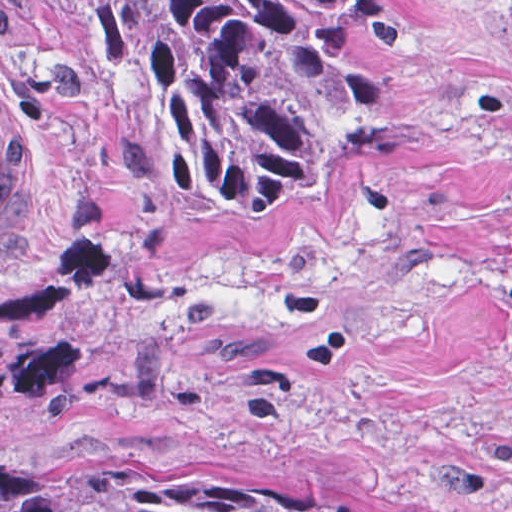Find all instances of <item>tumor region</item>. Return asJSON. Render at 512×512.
Instances as JSON below:
<instances>
[{
	"label": "tumor region",
	"mask_w": 512,
	"mask_h": 512,
	"mask_svg": "<svg viewBox=\"0 0 512 512\" xmlns=\"http://www.w3.org/2000/svg\"><path fill=\"white\" fill-rule=\"evenodd\" d=\"M25 1L218 214L258 215L337 177L394 114L386 79L319 0ZM132 512L354 511L247 472Z\"/></svg>",
	"instance_id": "tumor-region-1"
}]
</instances>
